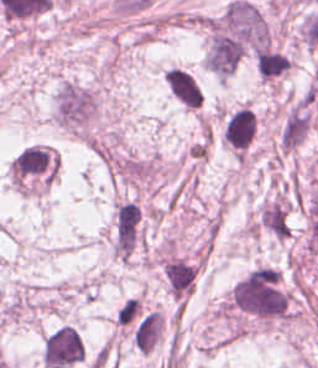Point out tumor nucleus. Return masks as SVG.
<instances>
[{
  "label": "tumor nucleus",
  "mask_w": 318,
  "mask_h": 368,
  "mask_svg": "<svg viewBox=\"0 0 318 368\" xmlns=\"http://www.w3.org/2000/svg\"><path fill=\"white\" fill-rule=\"evenodd\" d=\"M84 360V343L70 324L57 326L44 340L41 362L48 368H63Z\"/></svg>",
  "instance_id": "1"
}]
</instances>
